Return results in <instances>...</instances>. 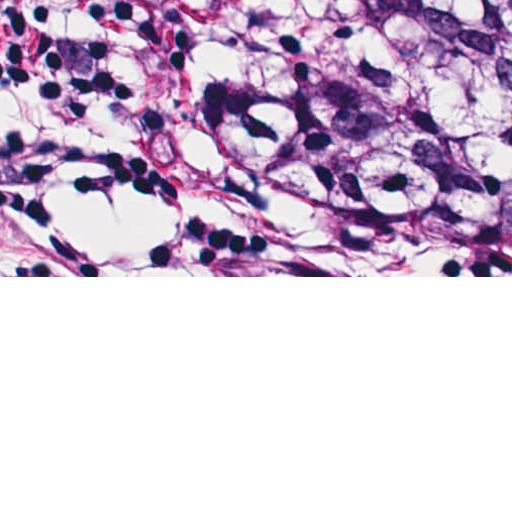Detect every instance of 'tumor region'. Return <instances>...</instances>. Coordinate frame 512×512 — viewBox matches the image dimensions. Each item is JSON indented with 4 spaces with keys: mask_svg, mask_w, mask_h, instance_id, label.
<instances>
[{
    "mask_svg": "<svg viewBox=\"0 0 512 512\" xmlns=\"http://www.w3.org/2000/svg\"><path fill=\"white\" fill-rule=\"evenodd\" d=\"M214 51L212 144L311 242L512 244V0H128Z\"/></svg>",
    "mask_w": 512,
    "mask_h": 512,
    "instance_id": "e687c5a6",
    "label": "tumor region"
}]
</instances>
